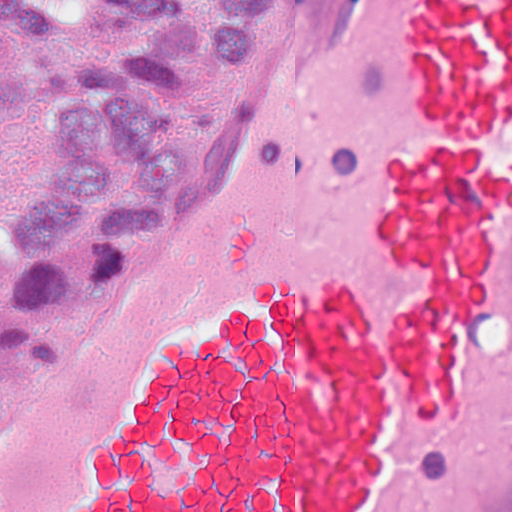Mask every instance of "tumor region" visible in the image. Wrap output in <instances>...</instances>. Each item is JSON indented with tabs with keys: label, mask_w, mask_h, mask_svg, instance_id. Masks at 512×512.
I'll return each mask as SVG.
<instances>
[{
	"label": "tumor region",
	"mask_w": 512,
	"mask_h": 512,
	"mask_svg": "<svg viewBox=\"0 0 512 512\" xmlns=\"http://www.w3.org/2000/svg\"><path fill=\"white\" fill-rule=\"evenodd\" d=\"M300 0H0V341L179 218Z\"/></svg>",
	"instance_id": "e687c5a6"
}]
</instances>
